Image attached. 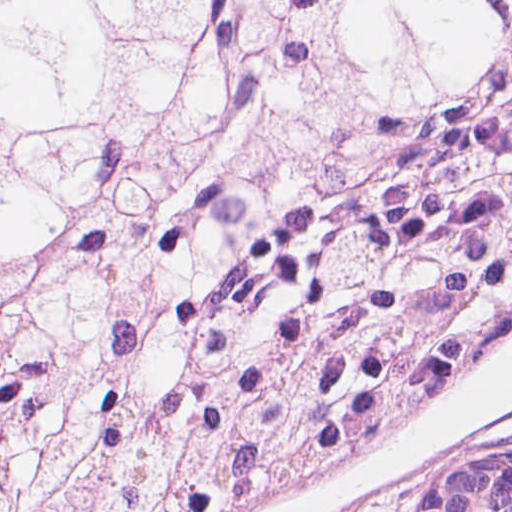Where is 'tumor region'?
<instances>
[{"mask_svg": "<svg viewBox=\"0 0 512 512\" xmlns=\"http://www.w3.org/2000/svg\"><path fill=\"white\" fill-rule=\"evenodd\" d=\"M511 330L512 1H0V512H233Z\"/></svg>", "mask_w": 512, "mask_h": 512, "instance_id": "tumor-region-1", "label": "tumor region"}]
</instances>
